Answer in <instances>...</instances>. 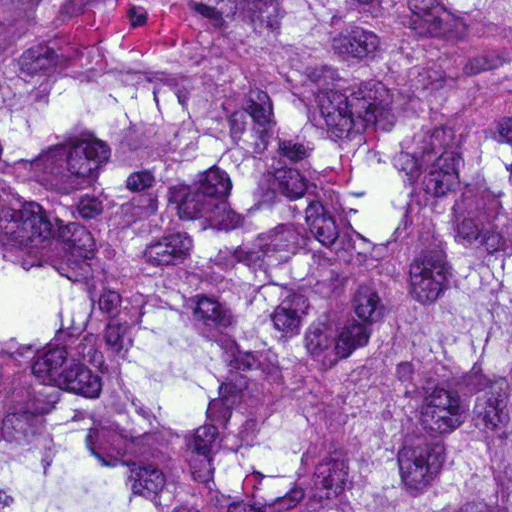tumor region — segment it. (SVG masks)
<instances>
[{"instance_id": "1", "label": "tumor region", "mask_w": 512, "mask_h": 512, "mask_svg": "<svg viewBox=\"0 0 512 512\" xmlns=\"http://www.w3.org/2000/svg\"><path fill=\"white\" fill-rule=\"evenodd\" d=\"M1 512H512V0H1Z\"/></svg>"}]
</instances>
